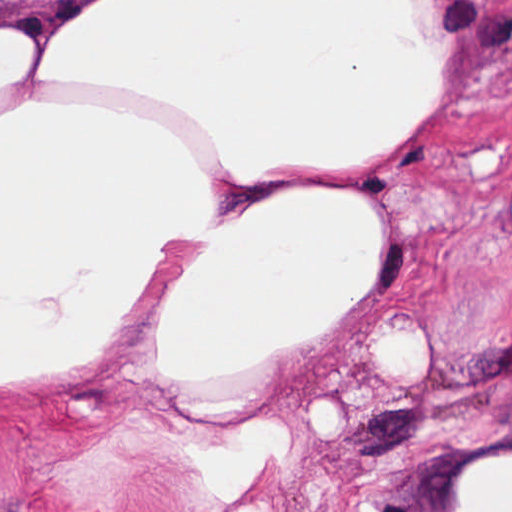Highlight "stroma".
<instances>
[{
  "label": "stroma",
  "mask_w": 512,
  "mask_h": 512,
  "mask_svg": "<svg viewBox=\"0 0 512 512\" xmlns=\"http://www.w3.org/2000/svg\"><path fill=\"white\" fill-rule=\"evenodd\" d=\"M84 1L0 0V16L28 20L39 45ZM431 2L453 91L416 140L378 162L217 193L259 203L324 185L363 197L379 229L360 301L284 366L195 405L146 366L148 283L102 359L52 386L0 392V512H460L475 464L512 459V0ZM490 146L502 170L479 176L472 149ZM404 320L416 368L389 381L376 335ZM326 398L340 433H322ZM260 420L282 443L251 489L218 496L216 465Z\"/></svg>",
  "instance_id": "1"
}]
</instances>
